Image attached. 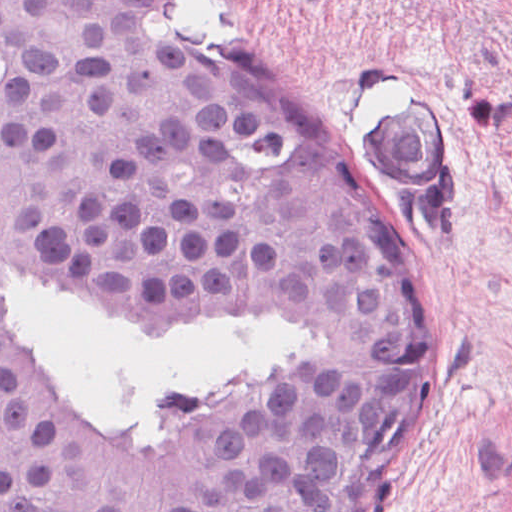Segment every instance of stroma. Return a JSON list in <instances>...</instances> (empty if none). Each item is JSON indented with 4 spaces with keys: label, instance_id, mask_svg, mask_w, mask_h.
<instances>
[{
    "label": "stroma",
    "instance_id": "1",
    "mask_svg": "<svg viewBox=\"0 0 512 512\" xmlns=\"http://www.w3.org/2000/svg\"><path fill=\"white\" fill-rule=\"evenodd\" d=\"M190 47L229 69L398 221L423 300L415 369L374 373L294 315L254 303L111 307L0 265V305L40 379L77 410L227 427L295 379L371 405L356 512H512V0H177ZM435 137V180L399 200L371 135L406 90ZM9 284L138 338H213L293 323L298 359L229 401H104L36 355Z\"/></svg>",
    "mask_w": 512,
    "mask_h": 512
}]
</instances>
